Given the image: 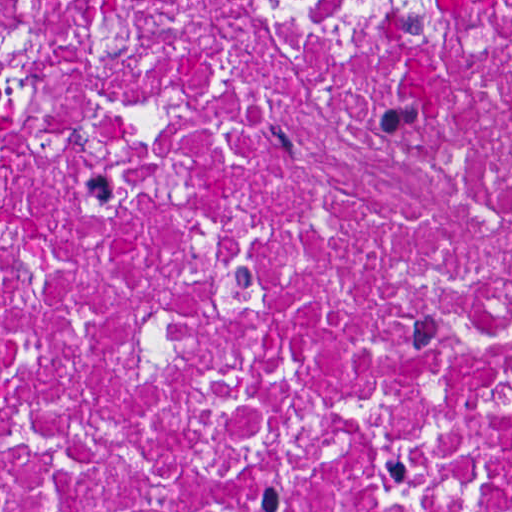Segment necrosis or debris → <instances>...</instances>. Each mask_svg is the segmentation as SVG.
<instances>
[{
    "label": "necrosis or debris",
    "mask_w": 512,
    "mask_h": 512,
    "mask_svg": "<svg viewBox=\"0 0 512 512\" xmlns=\"http://www.w3.org/2000/svg\"><path fill=\"white\" fill-rule=\"evenodd\" d=\"M1 512H512V0H1Z\"/></svg>",
    "instance_id": "1"
}]
</instances>
